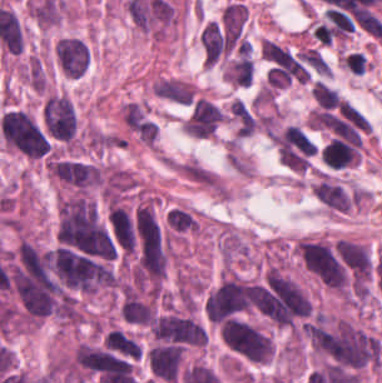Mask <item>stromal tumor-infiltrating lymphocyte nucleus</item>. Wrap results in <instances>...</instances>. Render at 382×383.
<instances>
[{
	"label": "stromal tumor-infiltrating lymphocyte nucleus",
	"instance_id": "bc302bb0",
	"mask_svg": "<svg viewBox=\"0 0 382 383\" xmlns=\"http://www.w3.org/2000/svg\"><path fill=\"white\" fill-rule=\"evenodd\" d=\"M312 192L328 208L346 212L349 210V198L345 192L324 178L313 186Z\"/></svg>",
	"mask_w": 382,
	"mask_h": 383
}]
</instances>
